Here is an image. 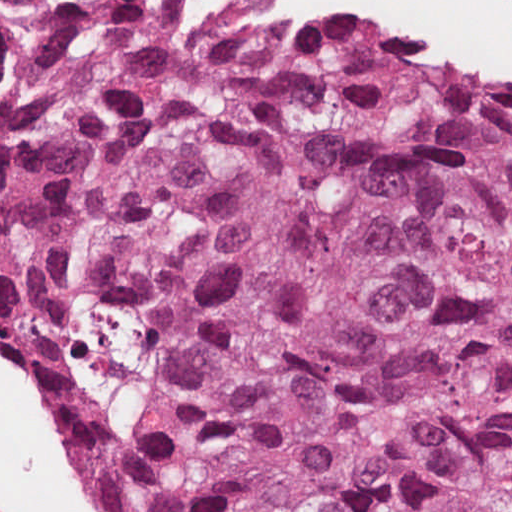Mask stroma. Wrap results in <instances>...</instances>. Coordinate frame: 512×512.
Here are the masks:
<instances>
[{
  "label": "stroma",
  "mask_w": 512,
  "mask_h": 512,
  "mask_svg": "<svg viewBox=\"0 0 512 512\" xmlns=\"http://www.w3.org/2000/svg\"><path fill=\"white\" fill-rule=\"evenodd\" d=\"M0 1H159L214 19L258 24H297L330 19L363 35L373 46L400 61L435 72L465 76L512 88V68L423 50L398 36L382 13L365 1H512V0H0ZM54 446V445H53ZM88 512H103L80 466L54 446Z\"/></svg>",
  "instance_id": "obj_1"
}]
</instances>
